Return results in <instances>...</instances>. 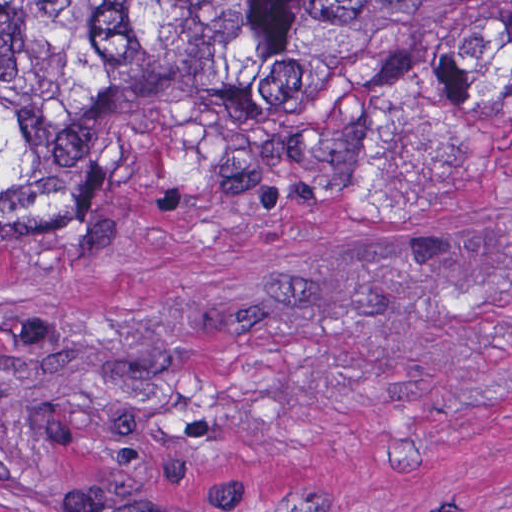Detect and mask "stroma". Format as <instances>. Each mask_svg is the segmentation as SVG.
Here are the masks:
<instances>
[{
    "mask_svg": "<svg viewBox=\"0 0 512 512\" xmlns=\"http://www.w3.org/2000/svg\"><path fill=\"white\" fill-rule=\"evenodd\" d=\"M0 512H512V102L368 203L0 252Z\"/></svg>",
    "mask_w": 512,
    "mask_h": 512,
    "instance_id": "1",
    "label": "stroma"
}]
</instances>
